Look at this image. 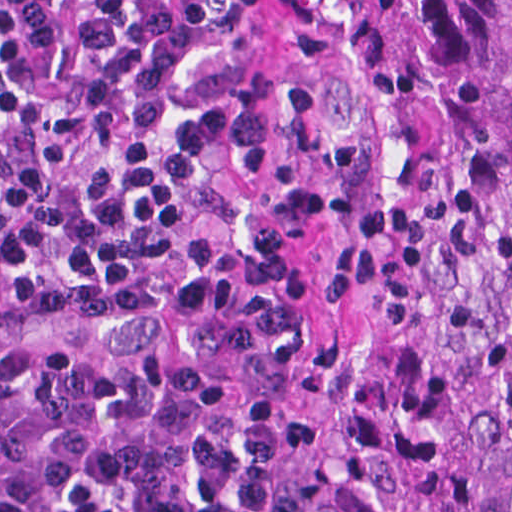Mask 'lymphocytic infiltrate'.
I'll use <instances>...</instances> for the list:
<instances>
[{
    "mask_svg": "<svg viewBox=\"0 0 512 512\" xmlns=\"http://www.w3.org/2000/svg\"><path fill=\"white\" fill-rule=\"evenodd\" d=\"M203 160L268 144L279 114L195 92L204 29L123 0ZM113 0H0V268L106 292L205 186ZM284 415L132 356L0 349V512H280Z\"/></svg>",
    "mask_w": 512,
    "mask_h": 512,
    "instance_id": "1",
    "label": "lymphocytic infiltrate"
}]
</instances>
